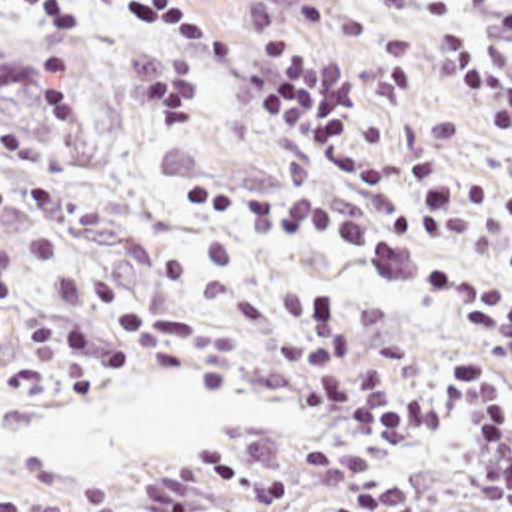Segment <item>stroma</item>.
<instances>
[{
  "instance_id": "stroma-1",
  "label": "stroma",
  "mask_w": 512,
  "mask_h": 512,
  "mask_svg": "<svg viewBox=\"0 0 512 512\" xmlns=\"http://www.w3.org/2000/svg\"><path fill=\"white\" fill-rule=\"evenodd\" d=\"M129 0H101L97 47L57 49L21 15L0 7V53L17 63L85 71L41 125L0 115V243L19 259L21 307L101 330L95 316L59 314L53 293L105 283L131 305L205 320L187 340L193 360L143 374L101 370L99 386L47 376L27 334L0 312V486L41 500V512H83L87 488H111L121 512H143L137 486L171 452L305 444L337 428L287 404L261 368L269 303L279 287L319 285L374 310L396 354L432 338H468L512 356V336L476 330L450 314L432 275L474 263L512 287V263L460 255L418 237L410 167L438 153L454 183H498L512 195V119L484 121L448 91L438 35H470L512 63V0H450L396 15L388 0H165L261 53L311 45L361 69L347 119V151L384 171L382 199H353L317 155L251 99L235 69L173 41L165 25L133 15ZM183 181L255 193L319 195L355 211L367 249H329L277 227L237 229L179 205ZM179 374L213 388L277 400V414L213 438L147 444L113 464H51L7 436L69 396L119 380ZM426 444L378 464L422 512H496L470 414Z\"/></svg>"
}]
</instances>
